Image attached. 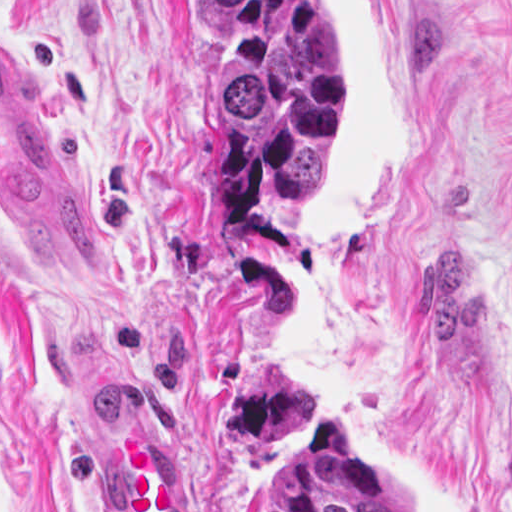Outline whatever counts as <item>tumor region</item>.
I'll return each mask as SVG.
<instances>
[{"label": "tumor region", "instance_id": "1", "mask_svg": "<svg viewBox=\"0 0 512 512\" xmlns=\"http://www.w3.org/2000/svg\"><path fill=\"white\" fill-rule=\"evenodd\" d=\"M211 41V204L231 227L320 210L341 148L329 0H196ZM261 512H414L406 485L343 415L315 421L261 479Z\"/></svg>", "mask_w": 512, "mask_h": 512}]
</instances>
